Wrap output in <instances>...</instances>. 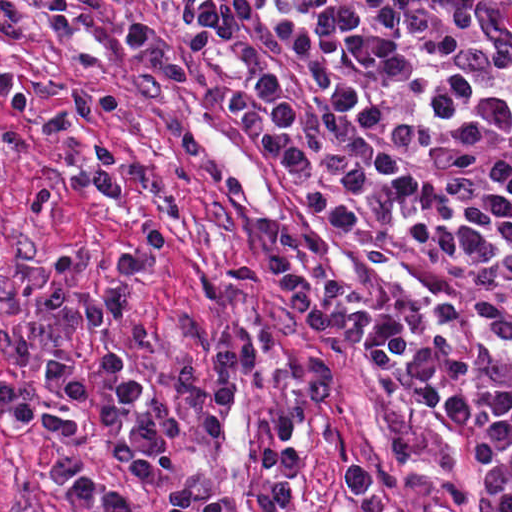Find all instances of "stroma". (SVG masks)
<instances>
[{
	"mask_svg": "<svg viewBox=\"0 0 512 512\" xmlns=\"http://www.w3.org/2000/svg\"><path fill=\"white\" fill-rule=\"evenodd\" d=\"M32 6L30 38L0 40V76L30 75L82 91H112L122 110L91 123L90 134L105 138L123 155L125 173L140 170L150 181L105 201L75 192L41 218L25 216V202L39 185L63 176L71 145L37 130L41 115L60 107L38 98L20 116L0 103V134L18 132L32 145L0 173V385L69 409L44 373V359L58 354L84 372L105 351L122 349L149 396H159L180 417L200 423L185 408L172 380L176 363L190 362L213 379L212 348L222 337L277 329L270 364L309 380L312 357L328 361L334 392L310 404L288 387H251L238 379V395L216 441L165 439V468L172 480L239 502L272 492L259 467L258 442L286 406L303 416V469L288 512H359L346 469L373 474L405 512H437L441 484L453 481L472 506L487 496L484 468L462 436L412 398L408 401L425 441V454L404 469H390L392 420L368 368L372 344L346 331L325 333L305 323L287 305L254 229L258 221L282 217L326 240L334 282L364 311L413 312L427 302V289L412 269L422 262L459 271L481 268L490 259L435 252L397 235L358 236L326 222L295 179L265 159L245 126L228 107V97L245 92L255 102L241 38L228 47H204L189 55L177 21L176 0H24ZM231 1H478L512 26V0H231ZM140 16L159 20L194 70L185 88L164 105L131 91L136 58L124 33ZM147 218H160L175 238L157 269L139 280L129 322L106 334L82 330L58 344L35 339L32 366L17 369L9 354L8 328L39 309L23 299L17 284L36 256L59 264L66 281L106 288L110 260L131 249ZM76 453L86 466L138 512H164L122 468L107 440L88 428L83 438L52 429L23 432L0 413V512H84L44 466L49 452ZM250 512H269L262 506Z\"/></svg>",
	"mask_w": 512,
	"mask_h": 512,
	"instance_id": "obj_1",
	"label": "stroma"
}]
</instances>
